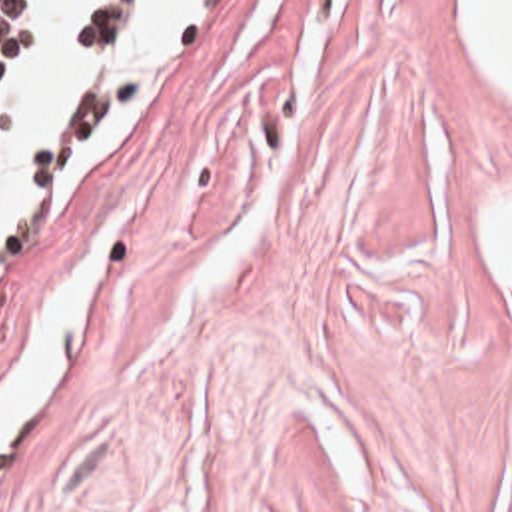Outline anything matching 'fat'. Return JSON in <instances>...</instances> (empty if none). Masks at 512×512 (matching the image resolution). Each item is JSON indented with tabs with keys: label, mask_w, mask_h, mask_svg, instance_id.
<instances>
[{
	"label": "fat",
	"mask_w": 512,
	"mask_h": 512,
	"mask_svg": "<svg viewBox=\"0 0 512 512\" xmlns=\"http://www.w3.org/2000/svg\"><path fill=\"white\" fill-rule=\"evenodd\" d=\"M460 20L490 78L512 92V0H460Z\"/></svg>",
	"instance_id": "53f6f03d"
}]
</instances>
